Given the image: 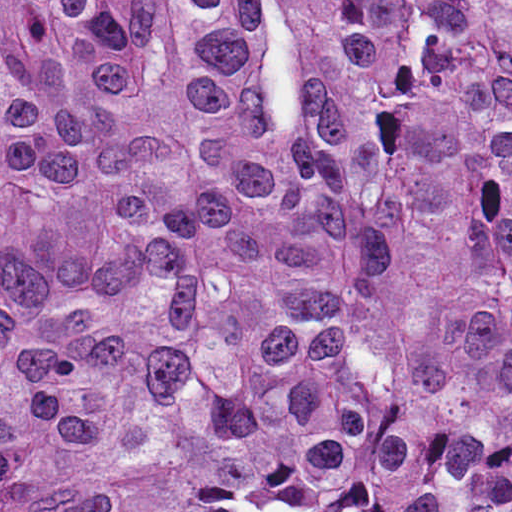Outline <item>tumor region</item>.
Returning <instances> with one entry per match:
<instances>
[{
    "mask_svg": "<svg viewBox=\"0 0 512 512\" xmlns=\"http://www.w3.org/2000/svg\"><path fill=\"white\" fill-rule=\"evenodd\" d=\"M0 512H512V0H0Z\"/></svg>",
    "mask_w": 512,
    "mask_h": 512,
    "instance_id": "1",
    "label": "tumor region"
}]
</instances>
